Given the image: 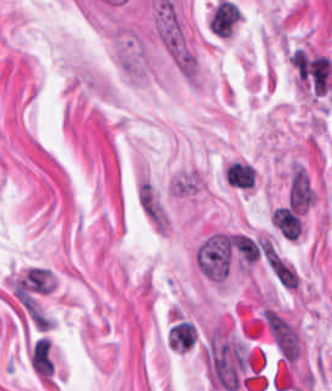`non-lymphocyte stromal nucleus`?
Returning <instances> with one entry per match:
<instances>
[{"instance_id":"non-lymphocyte-stromal-nucleus-3","label":"non-lymphocyte stromal nucleus","mask_w":332,"mask_h":391,"mask_svg":"<svg viewBox=\"0 0 332 391\" xmlns=\"http://www.w3.org/2000/svg\"><path fill=\"white\" fill-rule=\"evenodd\" d=\"M230 247L246 262L253 263L260 255L261 249L255 241L244 234H230Z\"/></svg>"},{"instance_id":"non-lymphocyte-stromal-nucleus-1","label":"non-lymphocyte stromal nucleus","mask_w":332,"mask_h":391,"mask_svg":"<svg viewBox=\"0 0 332 391\" xmlns=\"http://www.w3.org/2000/svg\"><path fill=\"white\" fill-rule=\"evenodd\" d=\"M137 205L148 224L159 234H168L171 217L167 205L155 184L142 178L137 188Z\"/></svg>"},{"instance_id":"non-lymphocyte-stromal-nucleus-2","label":"non-lymphocyte stromal nucleus","mask_w":332,"mask_h":391,"mask_svg":"<svg viewBox=\"0 0 332 391\" xmlns=\"http://www.w3.org/2000/svg\"><path fill=\"white\" fill-rule=\"evenodd\" d=\"M231 251L224 233L207 238L197 249L196 260L203 274L222 281L230 266Z\"/></svg>"}]
</instances>
